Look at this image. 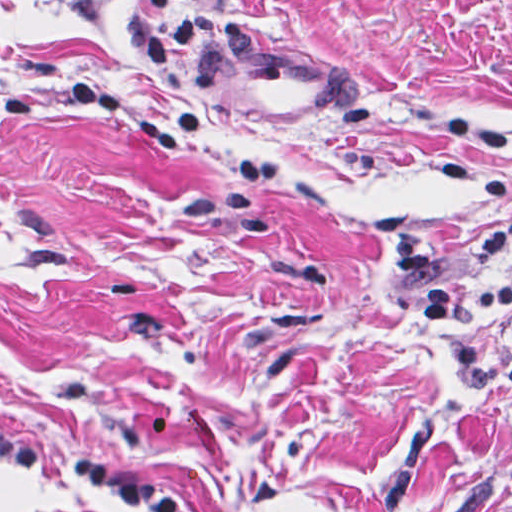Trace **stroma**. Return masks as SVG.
<instances>
[{"instance_id": "obj_1", "label": "stroma", "mask_w": 512, "mask_h": 512, "mask_svg": "<svg viewBox=\"0 0 512 512\" xmlns=\"http://www.w3.org/2000/svg\"><path fill=\"white\" fill-rule=\"evenodd\" d=\"M510 211L512 0H0V422L30 445L197 512H512V387L422 309ZM0 512L141 511L0 459Z\"/></svg>"}]
</instances>
